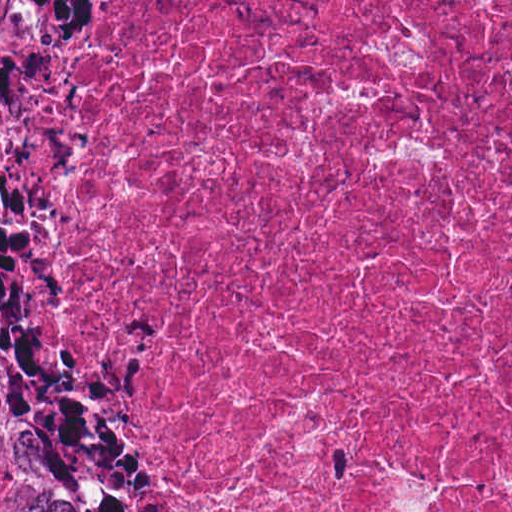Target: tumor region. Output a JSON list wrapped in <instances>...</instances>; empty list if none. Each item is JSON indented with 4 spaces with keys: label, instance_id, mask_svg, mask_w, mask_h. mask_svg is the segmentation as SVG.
Listing matches in <instances>:
<instances>
[{
    "label": "tumor region",
    "instance_id": "1",
    "mask_svg": "<svg viewBox=\"0 0 512 512\" xmlns=\"http://www.w3.org/2000/svg\"><path fill=\"white\" fill-rule=\"evenodd\" d=\"M135 3L0 0V512H125L63 399V200Z\"/></svg>",
    "mask_w": 512,
    "mask_h": 512
}]
</instances>
